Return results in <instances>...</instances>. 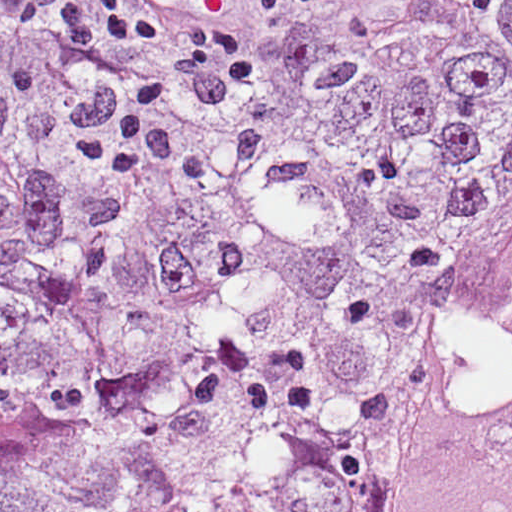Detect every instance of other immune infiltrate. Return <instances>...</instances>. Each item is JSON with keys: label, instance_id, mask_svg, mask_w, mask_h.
I'll list each match as a JSON object with an SVG mask.
<instances>
[{"label": "other immune infiltrate", "instance_id": "1", "mask_svg": "<svg viewBox=\"0 0 512 512\" xmlns=\"http://www.w3.org/2000/svg\"><path fill=\"white\" fill-rule=\"evenodd\" d=\"M273 1L44 0L24 19L65 11L76 47L138 89L126 117ZM41 178L35 176L10 106L0 101V185L18 195L17 203Z\"/></svg>", "mask_w": 512, "mask_h": 512}]
</instances>
